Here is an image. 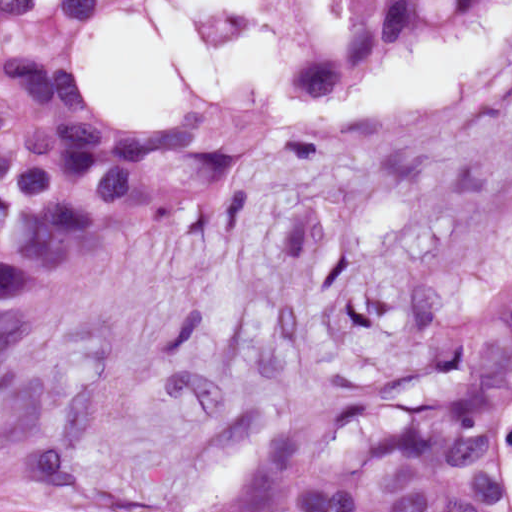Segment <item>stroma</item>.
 <instances>
[{"mask_svg":"<svg viewBox=\"0 0 512 512\" xmlns=\"http://www.w3.org/2000/svg\"><path fill=\"white\" fill-rule=\"evenodd\" d=\"M269 3L292 86L321 92L362 71L294 75L336 0ZM92 32L73 36L93 92ZM511 81L512 42L483 77L361 124L272 127L240 99L202 103L259 120V158L206 210L5 300L25 336L0 368V449L62 435L76 450L56 491L64 512H149L228 466L254 414L365 375L399 289L499 279L512 174L445 186L423 164Z\"/></svg>","mask_w":512,"mask_h":512,"instance_id":"stroma-1","label":"stroma"}]
</instances>
